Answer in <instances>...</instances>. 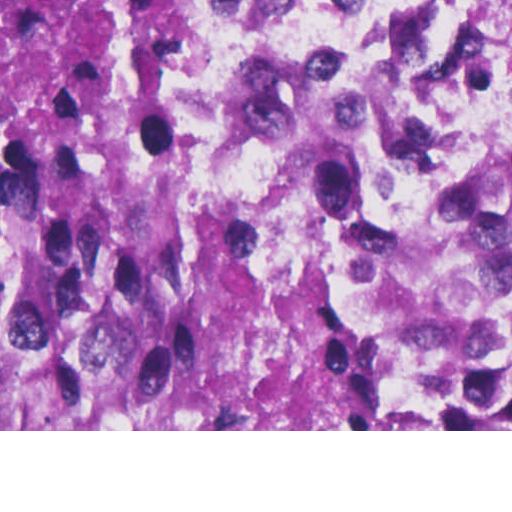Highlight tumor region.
I'll return each instance as SVG.
<instances>
[{
	"label": "tumor region",
	"mask_w": 512,
	"mask_h": 512,
	"mask_svg": "<svg viewBox=\"0 0 512 512\" xmlns=\"http://www.w3.org/2000/svg\"><path fill=\"white\" fill-rule=\"evenodd\" d=\"M241 0H0V429H512L397 393L212 167Z\"/></svg>",
	"instance_id": "1"
}]
</instances>
